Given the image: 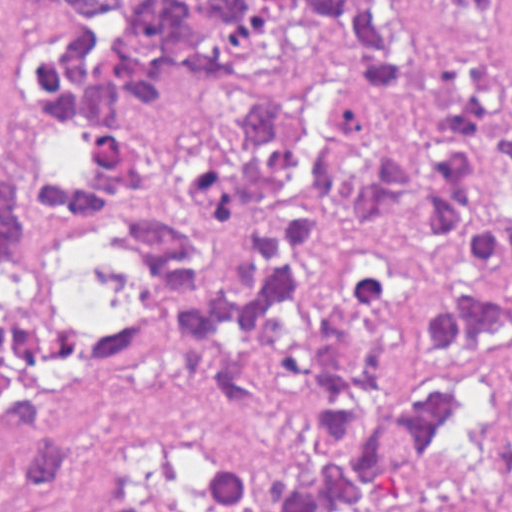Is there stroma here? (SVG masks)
<instances>
[{
    "label": "stroma",
    "instance_id": "1",
    "mask_svg": "<svg viewBox=\"0 0 512 512\" xmlns=\"http://www.w3.org/2000/svg\"><path fill=\"white\" fill-rule=\"evenodd\" d=\"M58 0H0V172L24 178L31 141L20 58ZM74 288L120 317L132 307V267L117 233L67 214ZM303 429L292 415L232 407L196 341L176 336L128 362L102 413L100 443L117 493L136 467L171 450L245 449L271 475L291 467ZM9 414L0 397V485ZM360 512H512V351L501 358L479 415L457 423L419 470L367 496Z\"/></svg>",
    "mask_w": 512,
    "mask_h": 512
}]
</instances>
